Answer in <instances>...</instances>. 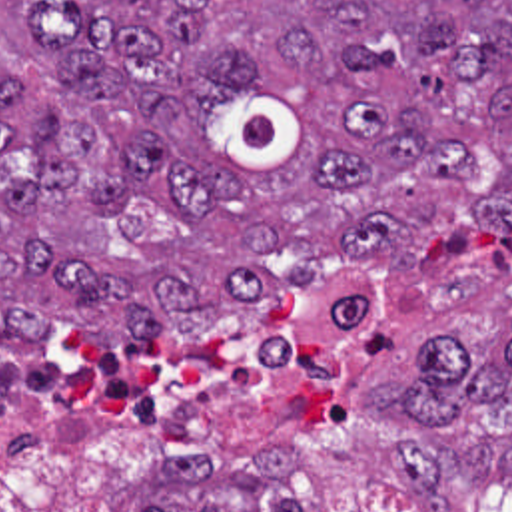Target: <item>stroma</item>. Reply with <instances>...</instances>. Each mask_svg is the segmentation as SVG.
<instances>
[{
  "mask_svg": "<svg viewBox=\"0 0 512 512\" xmlns=\"http://www.w3.org/2000/svg\"><path fill=\"white\" fill-rule=\"evenodd\" d=\"M319 265L315 289L287 293L361 297V327L343 357L271 389L191 460L129 464L87 490H29L0 476V512H418L414 494L390 478L398 420L366 405V383L406 377L432 335H458L484 351L502 345L512 311V229L428 233L400 267L329 253ZM63 327L79 329L53 319L51 333ZM171 331L107 345L141 349ZM470 488L480 512H512V480ZM448 512L466 510L454 500Z\"/></svg>",
  "mask_w": 512,
  "mask_h": 512,
  "instance_id": "1",
  "label": "stroma"
}]
</instances>
